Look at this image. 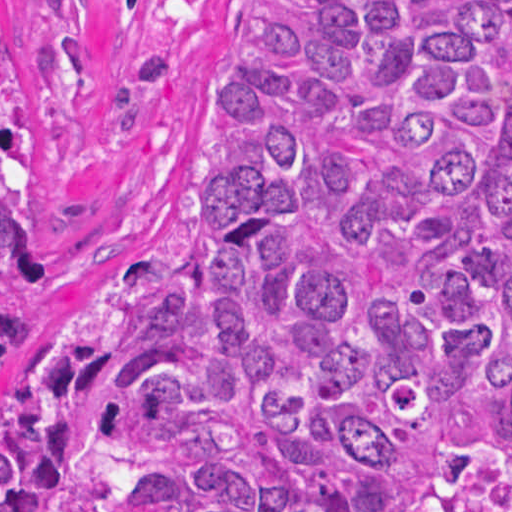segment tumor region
<instances>
[{
	"label": "tumor region",
	"instance_id": "obj_1",
	"mask_svg": "<svg viewBox=\"0 0 512 512\" xmlns=\"http://www.w3.org/2000/svg\"><path fill=\"white\" fill-rule=\"evenodd\" d=\"M36 303L0 0V512H512V0H266L11 399Z\"/></svg>",
	"mask_w": 512,
	"mask_h": 512
}]
</instances>
